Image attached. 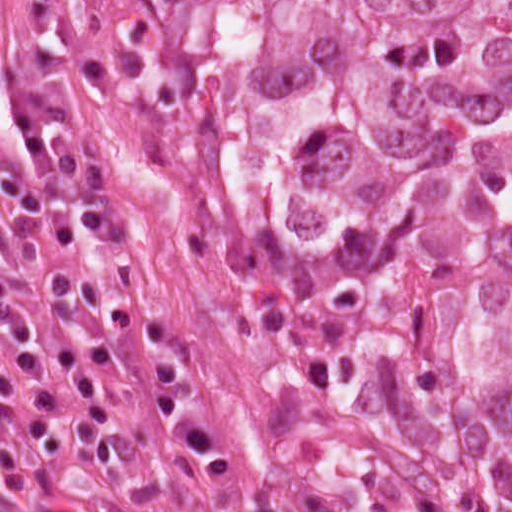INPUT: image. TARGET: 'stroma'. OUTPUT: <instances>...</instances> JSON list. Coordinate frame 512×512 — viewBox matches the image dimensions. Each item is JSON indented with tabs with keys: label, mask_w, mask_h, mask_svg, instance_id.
I'll return each mask as SVG.
<instances>
[{
	"label": "stroma",
	"mask_w": 512,
	"mask_h": 512,
	"mask_svg": "<svg viewBox=\"0 0 512 512\" xmlns=\"http://www.w3.org/2000/svg\"><path fill=\"white\" fill-rule=\"evenodd\" d=\"M17 82L38 101H68L78 111L73 127L55 139L57 151L94 158L107 177L122 231L93 235L81 205L57 173L46 180L48 200L72 217L76 235L67 245L42 240L44 261L19 288L20 303L39 335L41 356L72 410L86 402L65 376L55 349L100 341L113 351L126 388L147 400L161 397L155 351L144 336L91 310L61 318L47 300L53 272H83L108 298L169 323L184 341V380L189 395L211 422L230 459L212 472L201 461L163 439L122 398L109 371L97 377L134 438L122 461L104 475L70 469L27 436L25 419L37 412L73 443L79 434L57 408L35 402L24 390L13 337L0 322V361L11 369L19 391L0 399V421L52 475L116 512H201L250 487V482L295 512L251 461L234 435L215 368L217 333L209 302L168 212L161 180L142 138L126 90L109 52L95 0H0V81ZM26 141L12 109L0 107V174H21ZM13 207L0 193V263L14 267L21 242L10 227Z\"/></svg>",
	"instance_id": "stroma-1"
}]
</instances>
